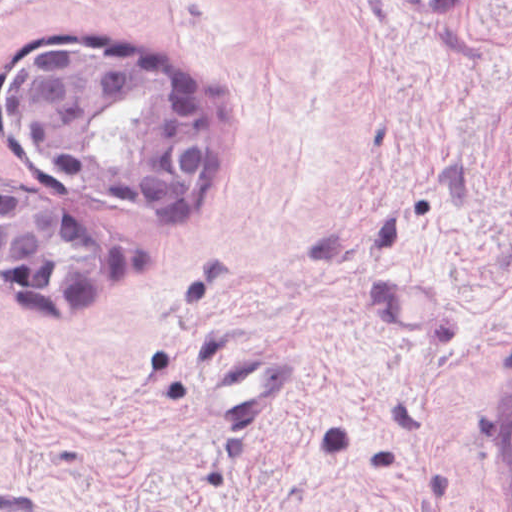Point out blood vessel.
I'll use <instances>...</instances> for the list:
<instances>
[{
    "instance_id": "blood-vessel-1",
    "label": "blood vessel",
    "mask_w": 512,
    "mask_h": 512,
    "mask_svg": "<svg viewBox=\"0 0 512 512\" xmlns=\"http://www.w3.org/2000/svg\"><path fill=\"white\" fill-rule=\"evenodd\" d=\"M282 345V344H281ZM257 351L219 363L211 381L209 407L237 430H265L283 415L295 376L294 351ZM0 512H149L73 508L50 489L32 482L5 480Z\"/></svg>"
}]
</instances>
